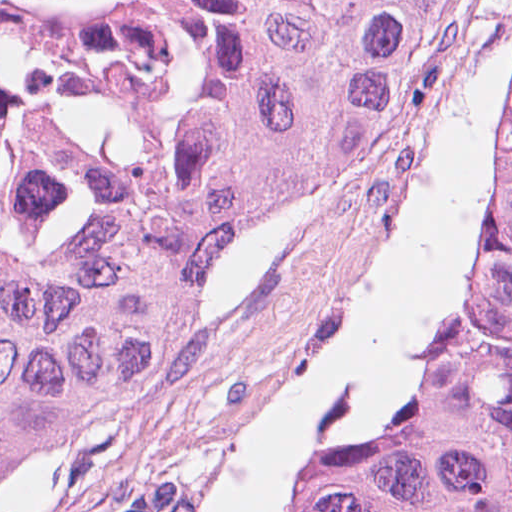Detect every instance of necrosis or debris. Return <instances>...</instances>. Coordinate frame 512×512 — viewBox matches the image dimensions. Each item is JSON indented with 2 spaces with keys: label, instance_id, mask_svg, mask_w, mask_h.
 <instances>
[{
  "label": "necrosis or debris",
  "instance_id": "necrosis-or-debris-1",
  "mask_svg": "<svg viewBox=\"0 0 512 512\" xmlns=\"http://www.w3.org/2000/svg\"><path fill=\"white\" fill-rule=\"evenodd\" d=\"M189 86L187 0H0V282L138 218Z\"/></svg>",
  "mask_w": 512,
  "mask_h": 512
}]
</instances>
